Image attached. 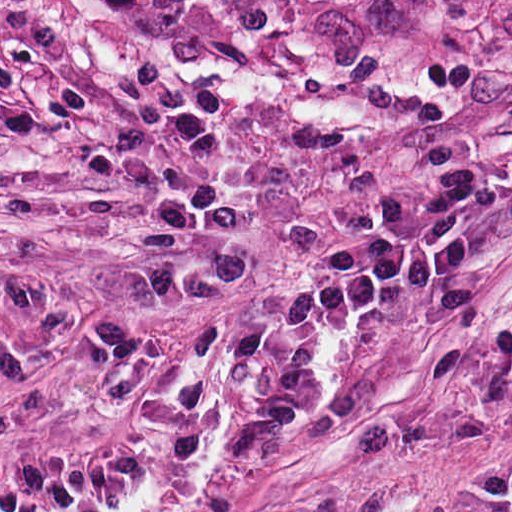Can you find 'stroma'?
<instances>
[{
    "label": "stroma",
    "mask_w": 512,
    "mask_h": 512,
    "mask_svg": "<svg viewBox=\"0 0 512 512\" xmlns=\"http://www.w3.org/2000/svg\"><path fill=\"white\" fill-rule=\"evenodd\" d=\"M512 161V0H0V512H512V181L474 251L329 323L265 452L226 439L311 283L431 147Z\"/></svg>",
    "instance_id": "obj_1"
}]
</instances>
